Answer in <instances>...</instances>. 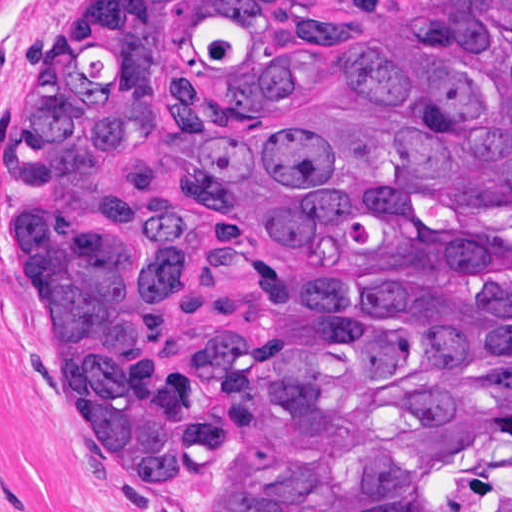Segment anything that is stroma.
<instances>
[{"instance_id": "1", "label": "stroma", "mask_w": 512, "mask_h": 512, "mask_svg": "<svg viewBox=\"0 0 512 512\" xmlns=\"http://www.w3.org/2000/svg\"><path fill=\"white\" fill-rule=\"evenodd\" d=\"M84 0H0V512H160L50 376L16 229V101Z\"/></svg>"}]
</instances>
